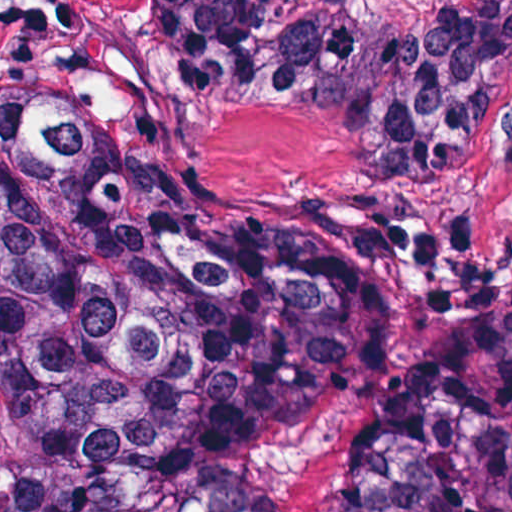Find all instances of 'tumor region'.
<instances>
[{
    "instance_id": "tumor-region-1",
    "label": "tumor region",
    "mask_w": 512,
    "mask_h": 512,
    "mask_svg": "<svg viewBox=\"0 0 512 512\" xmlns=\"http://www.w3.org/2000/svg\"><path fill=\"white\" fill-rule=\"evenodd\" d=\"M182 104L474 154L512 0H153ZM0 512H512V274L359 206L198 210L0 77Z\"/></svg>"
}]
</instances>
